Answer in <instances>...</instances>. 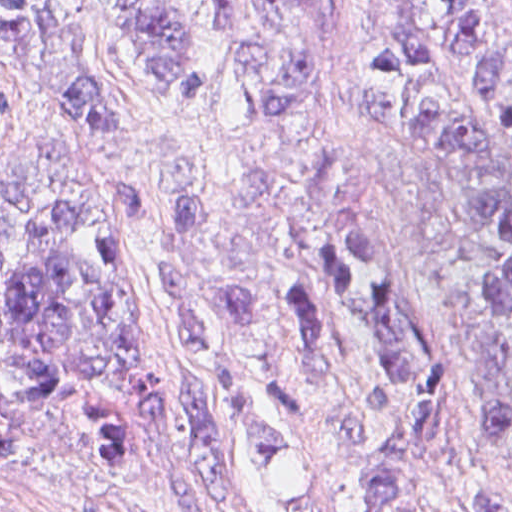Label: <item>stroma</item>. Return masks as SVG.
<instances>
[{
    "instance_id": "35a3bbf8",
    "label": "stroma",
    "mask_w": 512,
    "mask_h": 512,
    "mask_svg": "<svg viewBox=\"0 0 512 512\" xmlns=\"http://www.w3.org/2000/svg\"><path fill=\"white\" fill-rule=\"evenodd\" d=\"M308 1L315 35L355 118L368 178L432 304L452 365L449 409L424 463L430 498L442 512H512V490L478 462L480 427L504 380L480 262L465 247L458 209L434 158L382 140L360 123V81L374 51L380 0ZM489 1L512 23V0ZM179 12L195 41L192 80L179 93L161 89L97 0H91L84 46L94 83L127 127L117 164L99 161V178L157 200L152 178L165 150H186L213 170H230V138H250L252 130L240 55L214 5L194 0ZM57 132L0 43V167ZM164 236L163 212L159 232L122 259L123 299L140 317L139 358L151 380L201 383L175 357L172 316L159 286ZM104 466L110 469L73 459L47 431L25 426L18 447L0 454V512H225L181 415L149 422L122 463ZM248 504L258 512L249 497Z\"/></svg>"
}]
</instances>
